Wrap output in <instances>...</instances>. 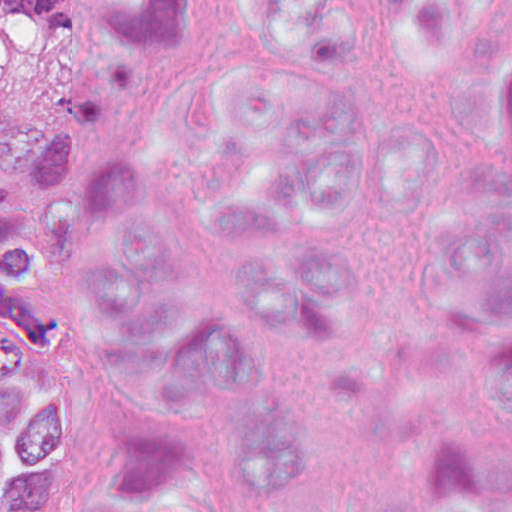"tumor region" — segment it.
Masks as SVG:
<instances>
[{
    "instance_id": "1",
    "label": "tumor region",
    "mask_w": 512,
    "mask_h": 512,
    "mask_svg": "<svg viewBox=\"0 0 512 512\" xmlns=\"http://www.w3.org/2000/svg\"><path fill=\"white\" fill-rule=\"evenodd\" d=\"M0 19L35 21L32 46L0 69V505L33 512L38 451L7 374L47 307L35 274L69 261L80 206L122 156L92 133L98 116L135 93L154 50L146 0H0ZM173 94L168 80L142 96L138 137H171Z\"/></svg>"
}]
</instances>
